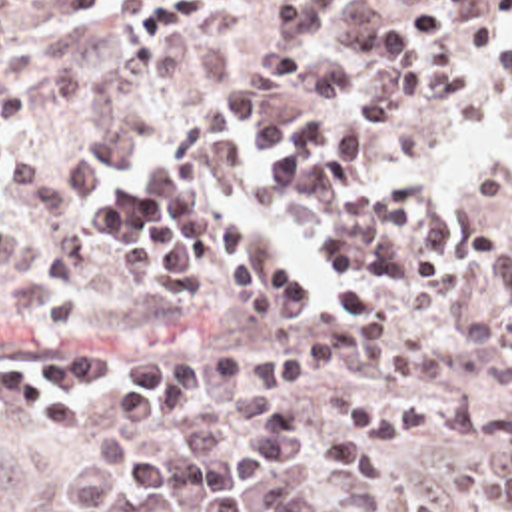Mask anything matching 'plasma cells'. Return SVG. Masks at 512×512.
Listing matches in <instances>:
<instances>
[{"mask_svg": "<svg viewBox=\"0 0 512 512\" xmlns=\"http://www.w3.org/2000/svg\"><path fill=\"white\" fill-rule=\"evenodd\" d=\"M490 0H285L271 36H217L195 46L211 88H241L251 74L285 88L323 46L366 66L464 30ZM91 0H0L1 28H47L81 16ZM0 186L21 190L61 248V272H79L103 224H141L213 204L231 186V150L207 130L147 116L111 122L69 144L39 142L29 82L0 98ZM37 278V244H0V300ZM185 456H107L65 472L57 498L85 512H360L319 490L331 458L297 434H243L227 448L215 424L183 426ZM0 512H15V484L0 480Z\"/></svg>", "mask_w": 512, "mask_h": 512, "instance_id": "9512152a", "label": "plasma cells"}]
</instances>
